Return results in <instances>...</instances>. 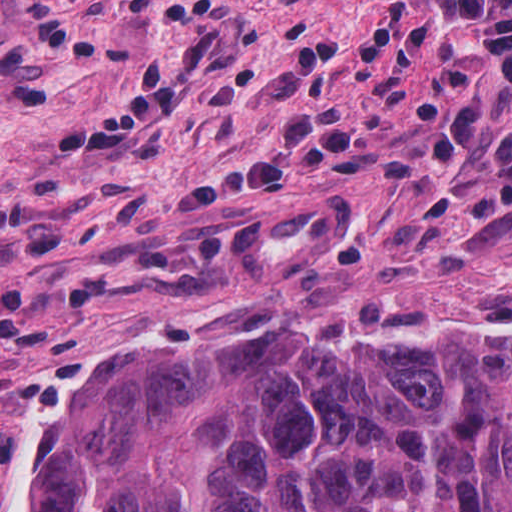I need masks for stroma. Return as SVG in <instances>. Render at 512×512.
<instances>
[{
    "mask_svg": "<svg viewBox=\"0 0 512 512\" xmlns=\"http://www.w3.org/2000/svg\"><path fill=\"white\" fill-rule=\"evenodd\" d=\"M423 249H512V0H0V512L113 350Z\"/></svg>",
    "mask_w": 512,
    "mask_h": 512,
    "instance_id": "1",
    "label": "stroma"
}]
</instances>
